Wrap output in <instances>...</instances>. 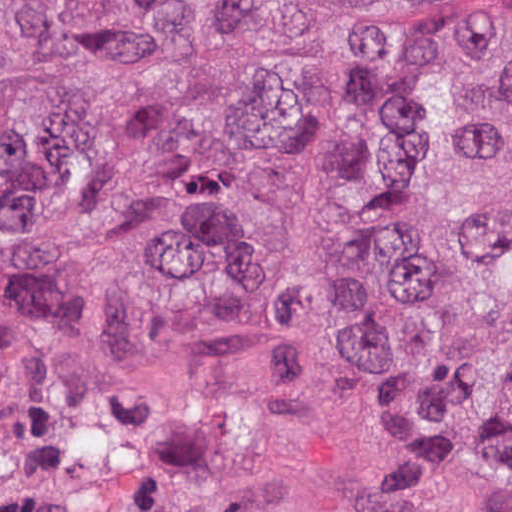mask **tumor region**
Listing matches in <instances>:
<instances>
[{
	"mask_svg": "<svg viewBox=\"0 0 512 512\" xmlns=\"http://www.w3.org/2000/svg\"><path fill=\"white\" fill-rule=\"evenodd\" d=\"M0 512H512V0H0Z\"/></svg>",
	"mask_w": 512,
	"mask_h": 512,
	"instance_id": "tumor-region-1",
	"label": "tumor region"
}]
</instances>
